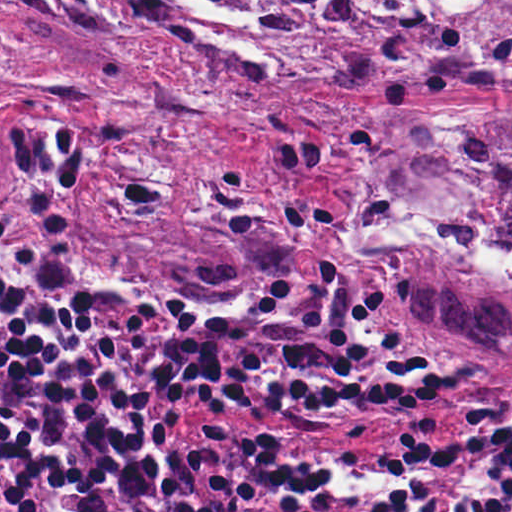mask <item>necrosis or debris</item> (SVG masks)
Returning <instances> with one entry per match:
<instances>
[{"instance_id":"obj_1","label":"necrosis or debris","mask_w":512,"mask_h":512,"mask_svg":"<svg viewBox=\"0 0 512 512\" xmlns=\"http://www.w3.org/2000/svg\"><path fill=\"white\" fill-rule=\"evenodd\" d=\"M319 1L331 24L403 44L414 59L474 70H512V0Z\"/></svg>"}]
</instances>
